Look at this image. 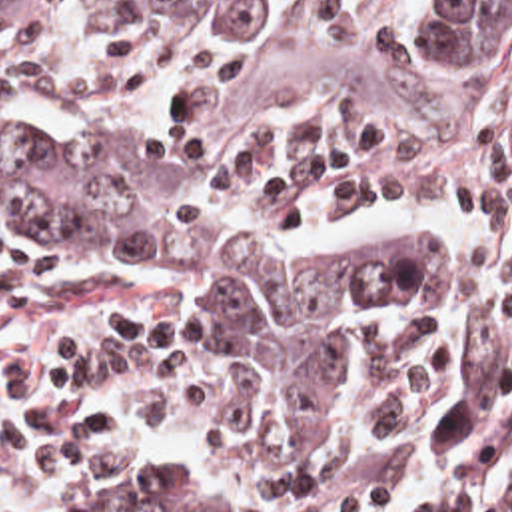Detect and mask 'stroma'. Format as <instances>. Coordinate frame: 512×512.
<instances>
[{"label": "stroma", "instance_id": "35a3bbf8", "mask_svg": "<svg viewBox=\"0 0 512 512\" xmlns=\"http://www.w3.org/2000/svg\"><path fill=\"white\" fill-rule=\"evenodd\" d=\"M0 23L41 39H101L175 31L201 41L211 57V109L219 123L321 119L360 131L372 143L430 161H512V101L490 111H327L261 101L251 71L223 37L161 17H55L0 11ZM0 135L53 139L99 175L155 205L207 225L241 249L267 257L331 255L378 229L434 233V281L420 291L354 303L333 333V361L321 395V443L295 451L281 429L277 393L245 327L225 309L185 295L133 267L81 271L19 247L0 229V512H293L255 489L233 465L201 445H185L171 481L149 493H75L43 475V431L61 373L93 337L147 311H203L249 365L265 401L273 453L299 477L317 467L339 429V363L354 327L368 315H422L458 287L462 227L452 209L382 213L345 233L283 225L193 191L145 149L79 135L57 121L0 115ZM512 369V337L488 343L446 387L432 427V512H458V447L476 415Z\"/></svg>", "mask_w": 512, "mask_h": 512}]
</instances>
